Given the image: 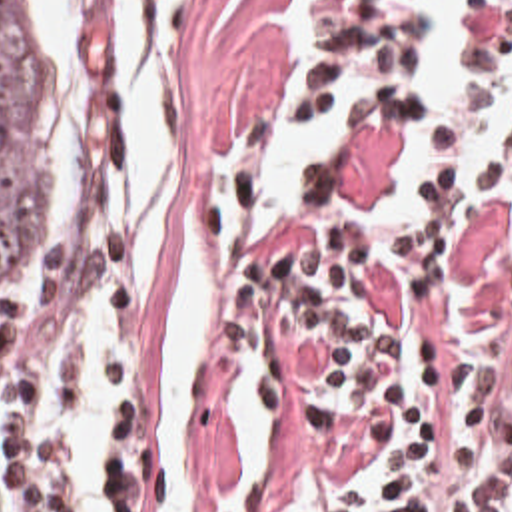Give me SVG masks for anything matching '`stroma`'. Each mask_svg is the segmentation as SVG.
<instances>
[{
	"label": "stroma",
	"mask_w": 512,
	"mask_h": 512,
	"mask_svg": "<svg viewBox=\"0 0 512 512\" xmlns=\"http://www.w3.org/2000/svg\"><path fill=\"white\" fill-rule=\"evenodd\" d=\"M51 49L72 99V209L51 249L0 279V388L45 338L51 313L108 285L112 438L120 512H168L150 446V372L180 281V249L206 201L220 243V323L188 438L194 512H402L418 494L464 482L512 448V187L484 195L442 271L362 261L374 328L436 352L484 396L488 444L428 486H392L354 420L300 386L292 354L298 257L330 215L388 191L400 175L398 129H350L310 161L290 209L248 239L262 193L266 133L280 87L290 0H196L188 27V129L178 199L156 275L126 279L114 225V65L90 25L80 61Z\"/></svg>",
	"instance_id": "obj_1"
}]
</instances>
